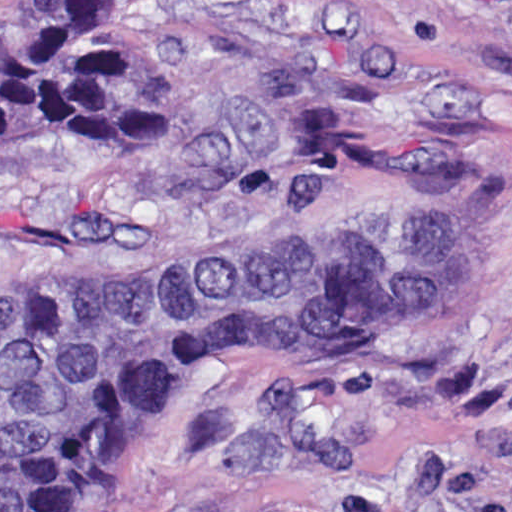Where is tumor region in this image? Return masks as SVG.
<instances>
[{"instance_id":"tumor-region-1","label":"tumor region","mask_w":512,"mask_h":512,"mask_svg":"<svg viewBox=\"0 0 512 512\" xmlns=\"http://www.w3.org/2000/svg\"><path fill=\"white\" fill-rule=\"evenodd\" d=\"M44 140H168L110 0H0V148ZM424 248L279 236L0 285V512L105 487L150 397L206 358L315 321H373V299Z\"/></svg>"}]
</instances>
